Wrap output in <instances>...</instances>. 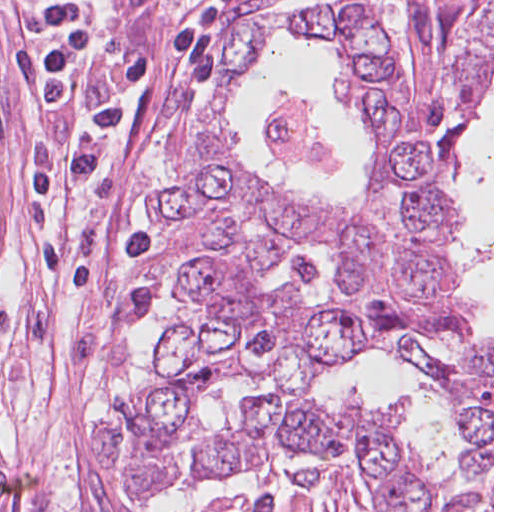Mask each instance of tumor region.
Segmentation results:
<instances>
[{"label":"tumor region","mask_w":512,"mask_h":512,"mask_svg":"<svg viewBox=\"0 0 512 512\" xmlns=\"http://www.w3.org/2000/svg\"><path fill=\"white\" fill-rule=\"evenodd\" d=\"M178 435L162 388L145 395L133 424L106 427L94 439L97 464L127 481L133 502H156L171 488ZM0 512H10V477L0 460Z\"/></svg>","instance_id":"tumor-region-1"}]
</instances>
